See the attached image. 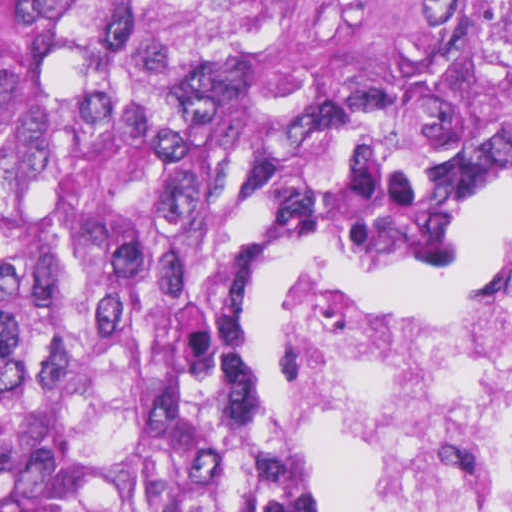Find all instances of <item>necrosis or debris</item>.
<instances>
[{"mask_svg": "<svg viewBox=\"0 0 512 512\" xmlns=\"http://www.w3.org/2000/svg\"><path fill=\"white\" fill-rule=\"evenodd\" d=\"M273 437L390 457L342 512H512V238L475 297L423 307L297 269L273 293Z\"/></svg>", "mask_w": 512, "mask_h": 512, "instance_id": "1", "label": "necrosis or debris"}]
</instances>
